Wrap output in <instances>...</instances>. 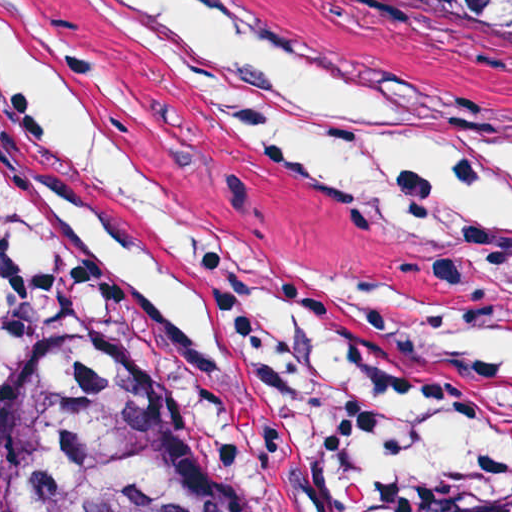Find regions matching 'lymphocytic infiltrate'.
Here are the masks:
<instances>
[{
    "label": "lymphocytic infiltrate",
    "mask_w": 512,
    "mask_h": 512,
    "mask_svg": "<svg viewBox=\"0 0 512 512\" xmlns=\"http://www.w3.org/2000/svg\"><path fill=\"white\" fill-rule=\"evenodd\" d=\"M9 203L0 184V405L32 375L91 346L118 291L91 269H6Z\"/></svg>",
    "instance_id": "1"
}]
</instances>
